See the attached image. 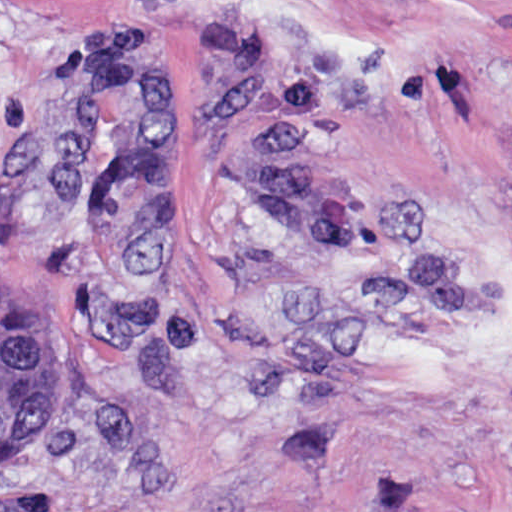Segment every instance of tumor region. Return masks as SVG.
Instances as JSON below:
<instances>
[{
  "label": "tumor region",
  "instance_id": "e687c5a6",
  "mask_svg": "<svg viewBox=\"0 0 512 512\" xmlns=\"http://www.w3.org/2000/svg\"><path fill=\"white\" fill-rule=\"evenodd\" d=\"M235 178L256 215L344 254V201L303 144L256 127L238 150ZM67 402L68 359L52 333L31 312L0 310V463L37 454Z\"/></svg>",
  "mask_w": 512,
  "mask_h": 512
}]
</instances>
